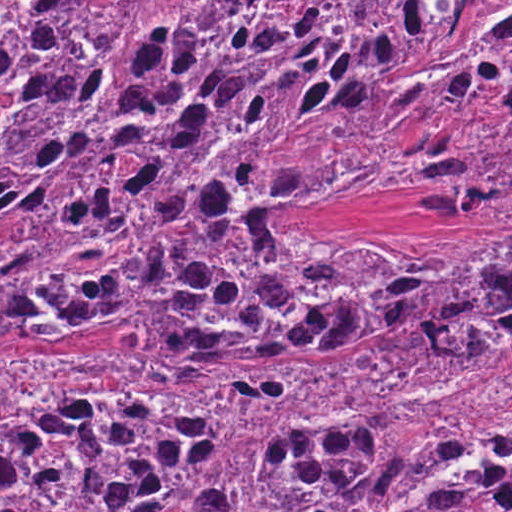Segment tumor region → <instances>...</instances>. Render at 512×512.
Here are the masks:
<instances>
[{
	"mask_svg": "<svg viewBox=\"0 0 512 512\" xmlns=\"http://www.w3.org/2000/svg\"><path fill=\"white\" fill-rule=\"evenodd\" d=\"M363 193L496 233H171ZM131 238L0 280L125 337L0 344V512H512V1H0V274Z\"/></svg>",
	"mask_w": 512,
	"mask_h": 512,
	"instance_id": "obj_1",
	"label": "tumor region"
}]
</instances>
